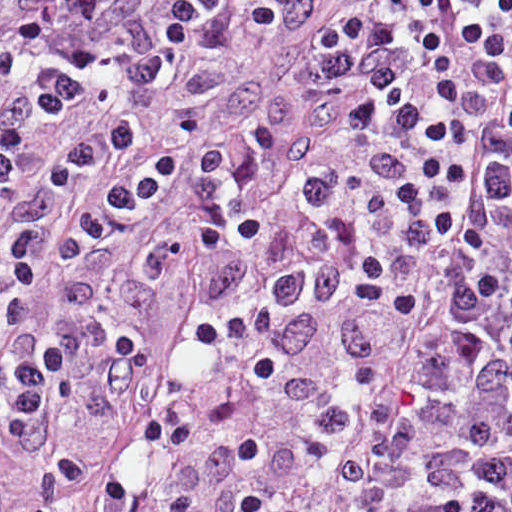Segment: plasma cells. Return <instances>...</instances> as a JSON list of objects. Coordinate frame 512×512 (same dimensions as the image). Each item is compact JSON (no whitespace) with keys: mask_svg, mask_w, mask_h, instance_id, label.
I'll use <instances>...</instances> for the list:
<instances>
[{"mask_svg":"<svg viewBox=\"0 0 512 512\" xmlns=\"http://www.w3.org/2000/svg\"><path fill=\"white\" fill-rule=\"evenodd\" d=\"M316 0H0V440L177 262L349 204L314 356V462L344 512H512V0H376L326 31L334 137L267 194L268 125L219 145L220 47ZM2 496H0L1 498Z\"/></svg>","mask_w":512,"mask_h":512,"instance_id":"1","label":"plasma cells"}]
</instances>
